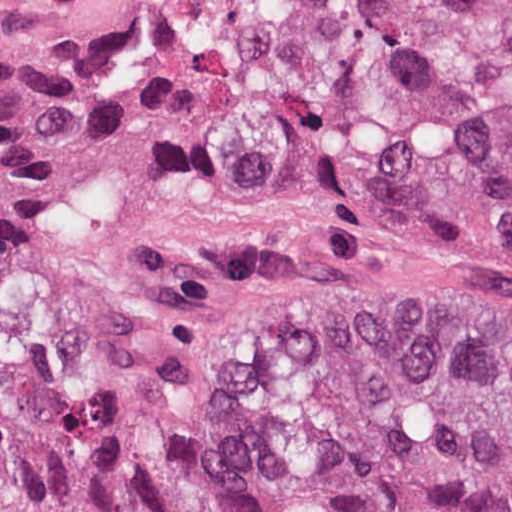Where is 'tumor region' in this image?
Here are the masks:
<instances>
[{"label":"tumor region","instance_id":"tumor-region-1","mask_svg":"<svg viewBox=\"0 0 512 512\" xmlns=\"http://www.w3.org/2000/svg\"><path fill=\"white\" fill-rule=\"evenodd\" d=\"M177 122L212 165L512 248V0H190ZM225 322L234 434L73 395L0 333V512H512L511 303L303 292Z\"/></svg>","mask_w":512,"mask_h":512}]
</instances>
